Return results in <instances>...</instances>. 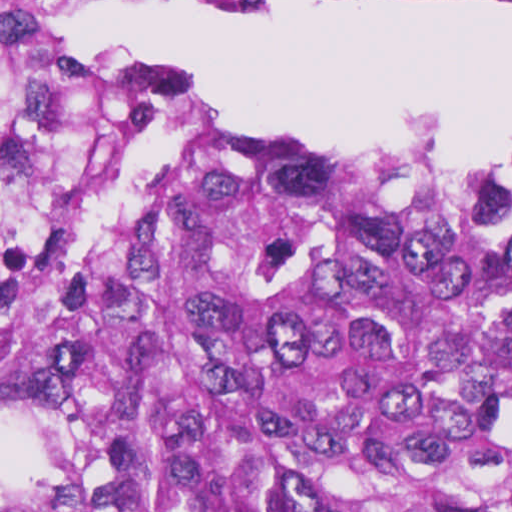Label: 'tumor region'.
Listing matches in <instances>:
<instances>
[{"instance_id":"obj_1","label":"tumor region","mask_w":512,"mask_h":512,"mask_svg":"<svg viewBox=\"0 0 512 512\" xmlns=\"http://www.w3.org/2000/svg\"><path fill=\"white\" fill-rule=\"evenodd\" d=\"M0 512H512V155L240 133L0 1Z\"/></svg>"}]
</instances>
